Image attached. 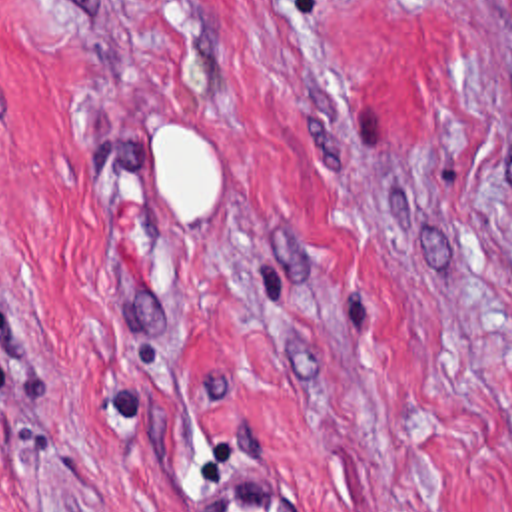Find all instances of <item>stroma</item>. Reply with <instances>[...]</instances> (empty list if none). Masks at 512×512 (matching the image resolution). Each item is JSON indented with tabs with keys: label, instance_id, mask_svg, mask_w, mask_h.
I'll return each mask as SVG.
<instances>
[{
	"label": "stroma",
	"instance_id": "35a3bbf8",
	"mask_svg": "<svg viewBox=\"0 0 512 512\" xmlns=\"http://www.w3.org/2000/svg\"><path fill=\"white\" fill-rule=\"evenodd\" d=\"M171 116L221 148L187 234ZM249 467L512 512V0H0V512Z\"/></svg>",
	"mask_w": 512,
	"mask_h": 512
}]
</instances>
